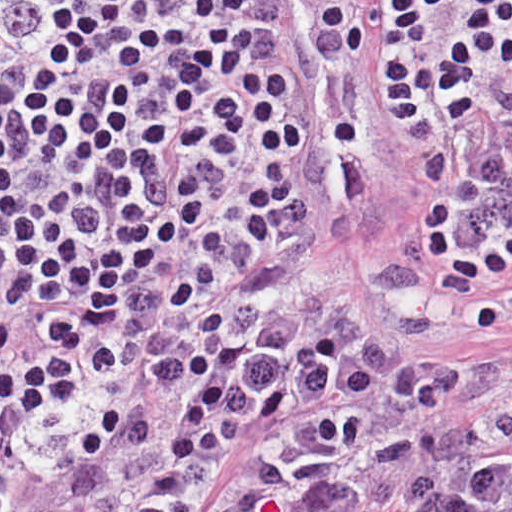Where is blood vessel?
I'll return each mask as SVG.
<instances>
[{
  "mask_svg": "<svg viewBox=\"0 0 512 512\" xmlns=\"http://www.w3.org/2000/svg\"><path fill=\"white\" fill-rule=\"evenodd\" d=\"M281 2L305 109L310 198L340 253L366 238L399 169V146L366 66L358 57L311 58L305 35L315 15Z\"/></svg>",
  "mask_w": 512,
  "mask_h": 512,
  "instance_id": "blood-vessel-1",
  "label": "blood vessel"
}]
</instances>
